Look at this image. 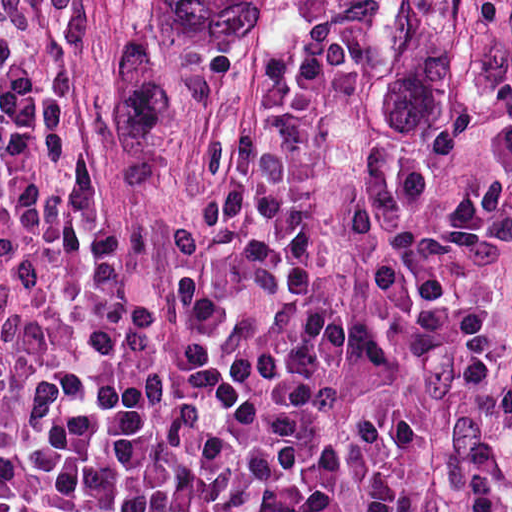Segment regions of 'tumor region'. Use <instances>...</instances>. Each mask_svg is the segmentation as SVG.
<instances>
[{
  "mask_svg": "<svg viewBox=\"0 0 512 512\" xmlns=\"http://www.w3.org/2000/svg\"><path fill=\"white\" fill-rule=\"evenodd\" d=\"M287 0H144V64L181 78H257Z\"/></svg>",
  "mask_w": 512,
  "mask_h": 512,
  "instance_id": "1",
  "label": "tumor region"
}]
</instances>
